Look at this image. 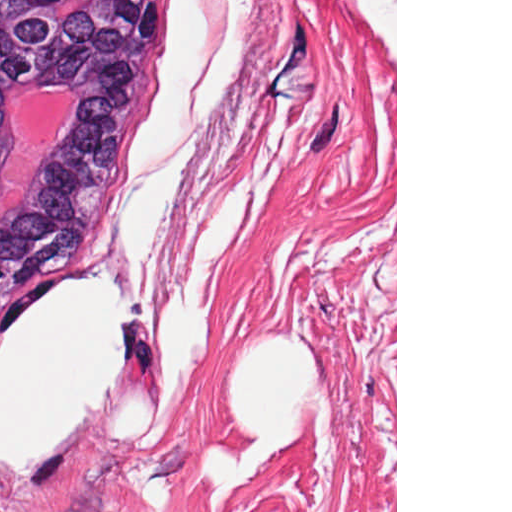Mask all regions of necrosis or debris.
Masks as SVG:
<instances>
[{"label": "necrosis or debris", "mask_w": 512, "mask_h": 512, "mask_svg": "<svg viewBox=\"0 0 512 512\" xmlns=\"http://www.w3.org/2000/svg\"><path fill=\"white\" fill-rule=\"evenodd\" d=\"M75 106L76 94L66 87H46L28 98L1 157L0 217L16 199Z\"/></svg>", "instance_id": "4bbe7bcc"}]
</instances>
